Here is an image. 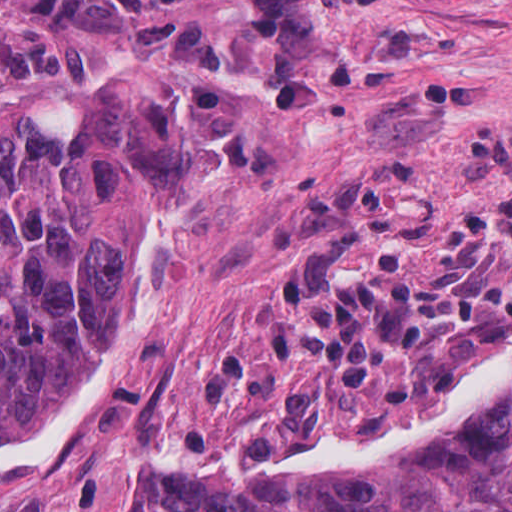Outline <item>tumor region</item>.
<instances>
[{
  "instance_id": "obj_1",
  "label": "tumor region",
  "mask_w": 512,
  "mask_h": 512,
  "mask_svg": "<svg viewBox=\"0 0 512 512\" xmlns=\"http://www.w3.org/2000/svg\"><path fill=\"white\" fill-rule=\"evenodd\" d=\"M241 158L216 87L169 67L101 86L73 131L0 114V436L69 398L118 338L153 245ZM113 512H512V398L334 492L206 470Z\"/></svg>"
}]
</instances>
